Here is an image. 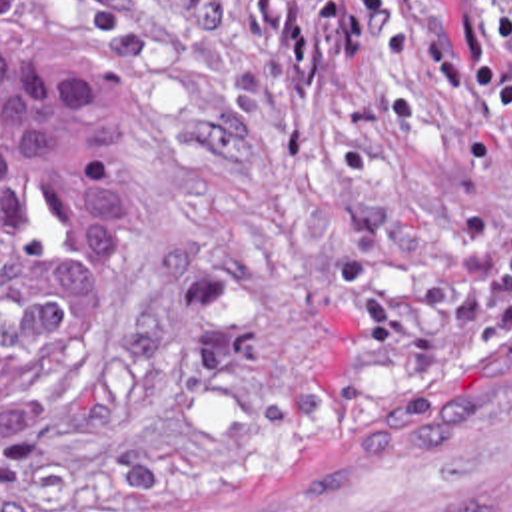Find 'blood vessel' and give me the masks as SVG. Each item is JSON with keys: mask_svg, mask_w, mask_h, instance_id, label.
<instances>
[{"mask_svg": "<svg viewBox=\"0 0 512 512\" xmlns=\"http://www.w3.org/2000/svg\"><path fill=\"white\" fill-rule=\"evenodd\" d=\"M134 512H512V350L350 382L208 501Z\"/></svg>", "mask_w": 512, "mask_h": 512, "instance_id": "blood-vessel-1", "label": "blood vessel"}]
</instances>
